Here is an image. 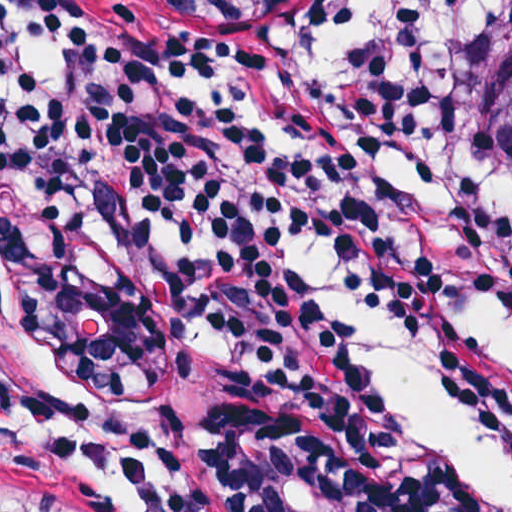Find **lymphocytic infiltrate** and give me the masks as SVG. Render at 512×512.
Returning a JSON list of instances; mask_svg holds the SVG:
<instances>
[{"instance_id":"f902f5d3","label":"lymphocytic infiltrate","mask_w":512,"mask_h":512,"mask_svg":"<svg viewBox=\"0 0 512 512\" xmlns=\"http://www.w3.org/2000/svg\"><path fill=\"white\" fill-rule=\"evenodd\" d=\"M495 2L336 0L270 27L171 19L165 34L132 0H0V64L24 40L73 50L0 118V198L63 214L245 320L334 415L373 419L391 399L448 390L512 471V345L447 309L512 298V208L461 154ZM288 143L317 153L375 233ZM143 210L207 236L205 263L141 258L127 223ZM307 246L398 325L383 390L288 266V249ZM392 478L406 512H507L476 476L394 435Z\"/></svg>"}]
</instances>
